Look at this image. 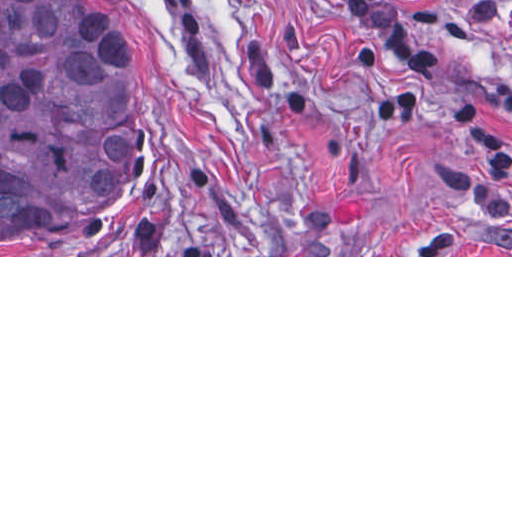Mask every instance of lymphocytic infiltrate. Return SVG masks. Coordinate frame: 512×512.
<instances>
[{
    "instance_id": "f902f5d3",
    "label": "lymphocytic infiltrate",
    "mask_w": 512,
    "mask_h": 512,
    "mask_svg": "<svg viewBox=\"0 0 512 512\" xmlns=\"http://www.w3.org/2000/svg\"><path fill=\"white\" fill-rule=\"evenodd\" d=\"M349 23L383 48V73L370 97L380 125H406L420 112L432 78V54L405 15L388 0H344ZM512 115V77L499 91ZM454 135L467 153L512 175V135L498 120L487 117L479 101L457 105ZM461 193L485 216L512 221V182L484 168L463 170Z\"/></svg>"
}]
</instances>
